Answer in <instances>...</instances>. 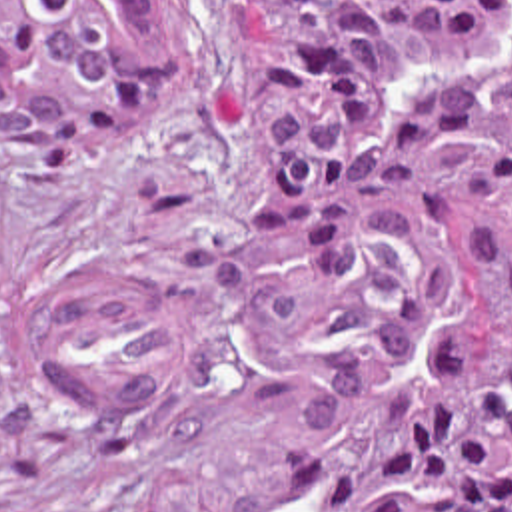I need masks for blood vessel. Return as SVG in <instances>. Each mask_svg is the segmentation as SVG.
I'll return each mask as SVG.
<instances>
[{
    "mask_svg": "<svg viewBox=\"0 0 512 512\" xmlns=\"http://www.w3.org/2000/svg\"><path fill=\"white\" fill-rule=\"evenodd\" d=\"M34 352L54 394L92 412L158 400L178 360V290L166 278L98 264L66 268L36 312Z\"/></svg>",
    "mask_w": 512,
    "mask_h": 512,
    "instance_id": "8fb6f2fc",
    "label": "blood vessel"
}]
</instances>
